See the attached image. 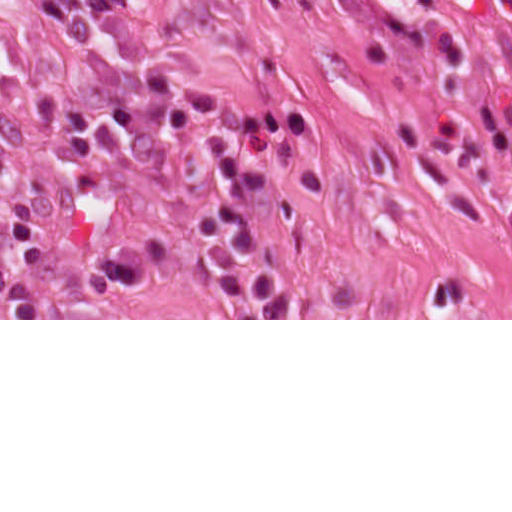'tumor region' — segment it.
I'll list each match as a JSON object with an SVG mask.
<instances>
[{"instance_id": "tumor-region-1", "label": "tumor region", "mask_w": 512, "mask_h": 512, "mask_svg": "<svg viewBox=\"0 0 512 512\" xmlns=\"http://www.w3.org/2000/svg\"><path fill=\"white\" fill-rule=\"evenodd\" d=\"M45 256L35 196L20 173L0 160V303L57 302L46 287Z\"/></svg>"}]
</instances>
